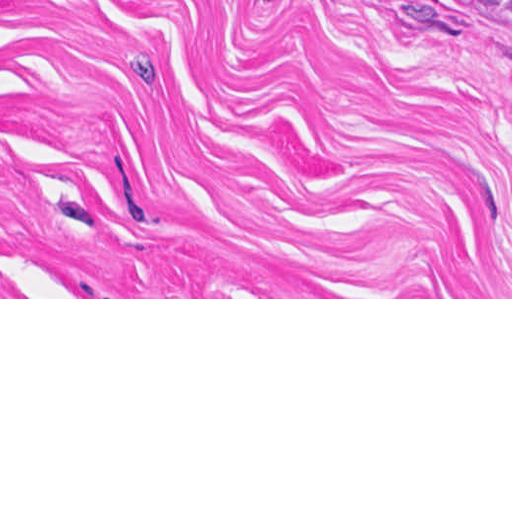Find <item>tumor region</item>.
<instances>
[{
	"mask_svg": "<svg viewBox=\"0 0 512 512\" xmlns=\"http://www.w3.org/2000/svg\"><path fill=\"white\" fill-rule=\"evenodd\" d=\"M487 23L512 34V0H460Z\"/></svg>",
	"mask_w": 512,
	"mask_h": 512,
	"instance_id": "obj_1",
	"label": "tumor region"
}]
</instances>
